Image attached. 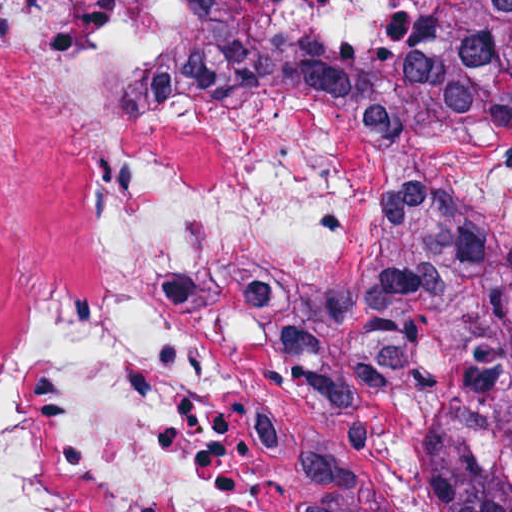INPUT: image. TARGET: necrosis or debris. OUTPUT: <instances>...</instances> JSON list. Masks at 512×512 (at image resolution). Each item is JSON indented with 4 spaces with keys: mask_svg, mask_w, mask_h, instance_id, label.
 I'll return each instance as SVG.
<instances>
[{
    "mask_svg": "<svg viewBox=\"0 0 512 512\" xmlns=\"http://www.w3.org/2000/svg\"><path fill=\"white\" fill-rule=\"evenodd\" d=\"M378 42L420 0H239ZM192 0H0V512H309L299 301L387 211L512 219V126L408 138L296 97H148Z\"/></svg>",
    "mask_w": 512,
    "mask_h": 512,
    "instance_id": "necrosis-or-debris-1",
    "label": "necrosis or debris"
}]
</instances>
